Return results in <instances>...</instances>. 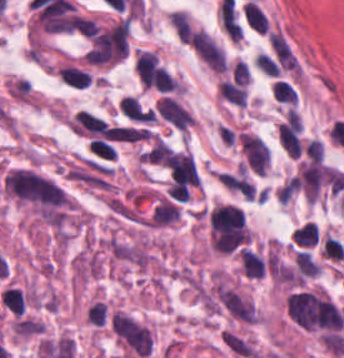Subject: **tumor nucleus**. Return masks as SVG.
I'll use <instances>...</instances> for the list:
<instances>
[{
  "label": "tumor nucleus",
  "instance_id": "tumor-nucleus-1",
  "mask_svg": "<svg viewBox=\"0 0 344 358\" xmlns=\"http://www.w3.org/2000/svg\"><path fill=\"white\" fill-rule=\"evenodd\" d=\"M110 324L116 337L137 355H146L151 346L149 328L129 314L114 312Z\"/></svg>",
  "mask_w": 344,
  "mask_h": 358
},
{
  "label": "tumor nucleus",
  "instance_id": "tumor-nucleus-2",
  "mask_svg": "<svg viewBox=\"0 0 344 358\" xmlns=\"http://www.w3.org/2000/svg\"><path fill=\"white\" fill-rule=\"evenodd\" d=\"M228 350L239 357H253L255 347L250 340L233 329H224L220 336Z\"/></svg>",
  "mask_w": 344,
  "mask_h": 358
}]
</instances>
